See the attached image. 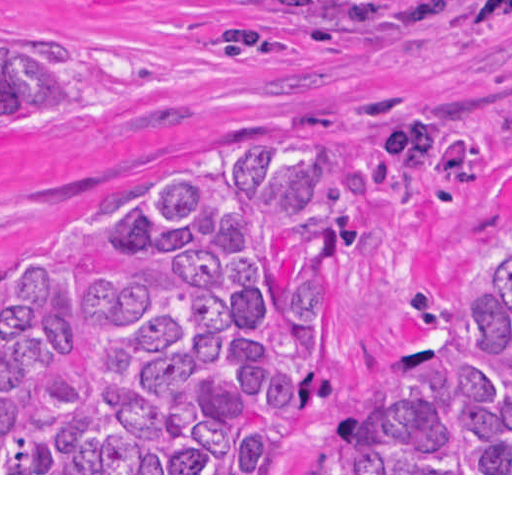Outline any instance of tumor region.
Masks as SVG:
<instances>
[{"label":"tumor region","instance_id":"obj_1","mask_svg":"<svg viewBox=\"0 0 512 512\" xmlns=\"http://www.w3.org/2000/svg\"><path fill=\"white\" fill-rule=\"evenodd\" d=\"M149 73L0 70V115L135 90ZM382 166L234 140L82 215L49 267L0 282V473H277L340 390L317 365L337 275L386 250L355 202L470 224L484 175L418 111ZM339 473H512V263L467 332L427 339L404 394L329 426Z\"/></svg>","mask_w":512,"mask_h":512}]
</instances>
